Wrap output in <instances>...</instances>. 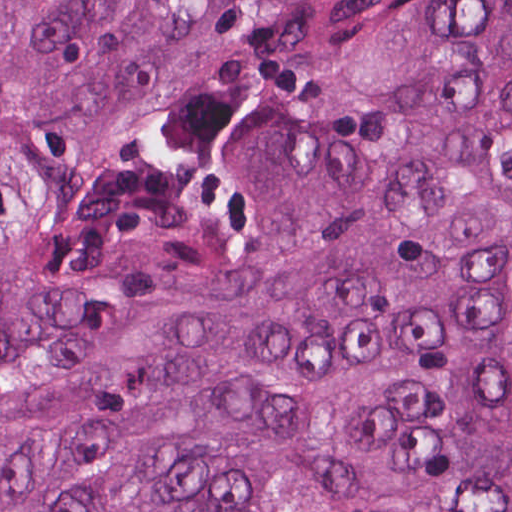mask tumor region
<instances>
[{
  "mask_svg": "<svg viewBox=\"0 0 512 512\" xmlns=\"http://www.w3.org/2000/svg\"><path fill=\"white\" fill-rule=\"evenodd\" d=\"M0 512H512V0H0Z\"/></svg>",
  "mask_w": 512,
  "mask_h": 512,
  "instance_id": "e687c5a6",
  "label": "tumor region"
}]
</instances>
